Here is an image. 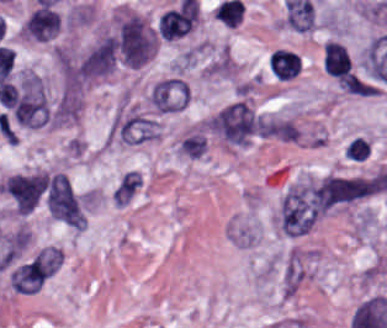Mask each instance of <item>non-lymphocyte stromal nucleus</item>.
<instances>
[{"label":"non-lymphocyte stromal nucleus","mask_w":387,"mask_h":328,"mask_svg":"<svg viewBox=\"0 0 387 328\" xmlns=\"http://www.w3.org/2000/svg\"><path fill=\"white\" fill-rule=\"evenodd\" d=\"M384 189L383 175H328L288 190L284 201L320 213Z\"/></svg>","instance_id":"non-lymphocyte-stromal-nucleus-1"},{"label":"non-lymphocyte stromal nucleus","mask_w":387,"mask_h":328,"mask_svg":"<svg viewBox=\"0 0 387 328\" xmlns=\"http://www.w3.org/2000/svg\"><path fill=\"white\" fill-rule=\"evenodd\" d=\"M216 135L230 145H244L260 134L262 118L244 99H236L212 118Z\"/></svg>","instance_id":"non-lymphocyte-stromal-nucleus-2"},{"label":"non-lymphocyte stromal nucleus","mask_w":387,"mask_h":328,"mask_svg":"<svg viewBox=\"0 0 387 328\" xmlns=\"http://www.w3.org/2000/svg\"><path fill=\"white\" fill-rule=\"evenodd\" d=\"M62 263V249L40 248L11 272V285L18 291H36Z\"/></svg>","instance_id":"non-lymphocyte-stromal-nucleus-3"},{"label":"non-lymphocyte stromal nucleus","mask_w":387,"mask_h":328,"mask_svg":"<svg viewBox=\"0 0 387 328\" xmlns=\"http://www.w3.org/2000/svg\"><path fill=\"white\" fill-rule=\"evenodd\" d=\"M12 115L22 124L37 126L47 121L46 94L39 75L23 74L13 105Z\"/></svg>","instance_id":"non-lymphocyte-stromal-nucleus-4"},{"label":"non-lymphocyte stromal nucleus","mask_w":387,"mask_h":328,"mask_svg":"<svg viewBox=\"0 0 387 328\" xmlns=\"http://www.w3.org/2000/svg\"><path fill=\"white\" fill-rule=\"evenodd\" d=\"M46 201L51 216L77 228L87 224L86 216L65 173L50 176Z\"/></svg>","instance_id":"non-lymphocyte-stromal-nucleus-5"},{"label":"non-lymphocyte stromal nucleus","mask_w":387,"mask_h":328,"mask_svg":"<svg viewBox=\"0 0 387 328\" xmlns=\"http://www.w3.org/2000/svg\"><path fill=\"white\" fill-rule=\"evenodd\" d=\"M117 46L123 60L137 66L149 57L155 36L137 15H130L119 27Z\"/></svg>","instance_id":"non-lymphocyte-stromal-nucleus-6"},{"label":"non-lymphocyte stromal nucleus","mask_w":387,"mask_h":328,"mask_svg":"<svg viewBox=\"0 0 387 328\" xmlns=\"http://www.w3.org/2000/svg\"><path fill=\"white\" fill-rule=\"evenodd\" d=\"M46 186L45 174H17L5 180L2 191L15 210L30 212Z\"/></svg>","instance_id":"non-lymphocyte-stromal-nucleus-7"},{"label":"non-lymphocyte stromal nucleus","mask_w":387,"mask_h":328,"mask_svg":"<svg viewBox=\"0 0 387 328\" xmlns=\"http://www.w3.org/2000/svg\"><path fill=\"white\" fill-rule=\"evenodd\" d=\"M160 126L155 116L137 111L120 115L110 132L120 142L139 143L157 137Z\"/></svg>","instance_id":"non-lymphocyte-stromal-nucleus-8"},{"label":"non-lymphocyte stromal nucleus","mask_w":387,"mask_h":328,"mask_svg":"<svg viewBox=\"0 0 387 328\" xmlns=\"http://www.w3.org/2000/svg\"><path fill=\"white\" fill-rule=\"evenodd\" d=\"M316 219V212L301 190L284 195L280 223L286 235L308 232Z\"/></svg>","instance_id":"non-lymphocyte-stromal-nucleus-9"},{"label":"non-lymphocyte stromal nucleus","mask_w":387,"mask_h":328,"mask_svg":"<svg viewBox=\"0 0 387 328\" xmlns=\"http://www.w3.org/2000/svg\"><path fill=\"white\" fill-rule=\"evenodd\" d=\"M186 80L166 77L149 91V102L157 111H171L184 107Z\"/></svg>","instance_id":"non-lymphocyte-stromal-nucleus-10"},{"label":"non-lymphocyte stromal nucleus","mask_w":387,"mask_h":328,"mask_svg":"<svg viewBox=\"0 0 387 328\" xmlns=\"http://www.w3.org/2000/svg\"><path fill=\"white\" fill-rule=\"evenodd\" d=\"M140 185L139 172H125L112 191L113 201L128 203Z\"/></svg>","instance_id":"non-lymphocyte-stromal-nucleus-11"}]
</instances>
